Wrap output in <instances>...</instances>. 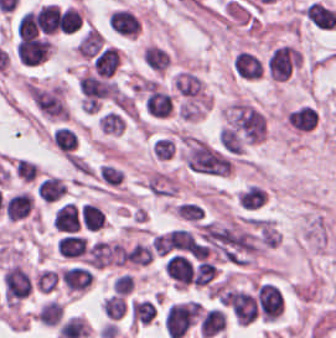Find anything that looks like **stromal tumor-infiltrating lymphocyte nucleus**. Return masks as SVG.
Wrapping results in <instances>:
<instances>
[{"instance_id":"4","label":"stromal tumor-infiltrating lymphocyte nucleus","mask_w":336,"mask_h":338,"mask_svg":"<svg viewBox=\"0 0 336 338\" xmlns=\"http://www.w3.org/2000/svg\"><path fill=\"white\" fill-rule=\"evenodd\" d=\"M106 26L115 35L132 37L138 29V19L125 7H118L106 16Z\"/></svg>"},{"instance_id":"9","label":"stromal tumor-infiltrating lymphocyte nucleus","mask_w":336,"mask_h":338,"mask_svg":"<svg viewBox=\"0 0 336 338\" xmlns=\"http://www.w3.org/2000/svg\"><path fill=\"white\" fill-rule=\"evenodd\" d=\"M306 17L315 27L322 29H332L336 21L332 9L313 0L306 9Z\"/></svg>"},{"instance_id":"12","label":"stromal tumor-infiltrating lymphocyte nucleus","mask_w":336,"mask_h":338,"mask_svg":"<svg viewBox=\"0 0 336 338\" xmlns=\"http://www.w3.org/2000/svg\"><path fill=\"white\" fill-rule=\"evenodd\" d=\"M145 105L152 114L167 115L172 107L171 95L151 87Z\"/></svg>"},{"instance_id":"3","label":"stromal tumor-infiltrating lymphocyte nucleus","mask_w":336,"mask_h":338,"mask_svg":"<svg viewBox=\"0 0 336 338\" xmlns=\"http://www.w3.org/2000/svg\"><path fill=\"white\" fill-rule=\"evenodd\" d=\"M84 261L89 269H99L114 264L112 243L98 238L90 240L86 245Z\"/></svg>"},{"instance_id":"14","label":"stromal tumor-infiltrating lymphocyte nucleus","mask_w":336,"mask_h":338,"mask_svg":"<svg viewBox=\"0 0 336 338\" xmlns=\"http://www.w3.org/2000/svg\"><path fill=\"white\" fill-rule=\"evenodd\" d=\"M124 122L119 109H105L98 117V125L104 133H121Z\"/></svg>"},{"instance_id":"1","label":"stromal tumor-infiltrating lymphocyte nucleus","mask_w":336,"mask_h":338,"mask_svg":"<svg viewBox=\"0 0 336 338\" xmlns=\"http://www.w3.org/2000/svg\"><path fill=\"white\" fill-rule=\"evenodd\" d=\"M162 323L167 337L180 338L191 324L188 302L168 305Z\"/></svg>"},{"instance_id":"8","label":"stromal tumor-infiltrating lymphocyte nucleus","mask_w":336,"mask_h":338,"mask_svg":"<svg viewBox=\"0 0 336 338\" xmlns=\"http://www.w3.org/2000/svg\"><path fill=\"white\" fill-rule=\"evenodd\" d=\"M32 208L29 194L19 192L7 198L4 213L7 220H18L26 217Z\"/></svg>"},{"instance_id":"17","label":"stromal tumor-infiltrating lymphocyte nucleus","mask_w":336,"mask_h":338,"mask_svg":"<svg viewBox=\"0 0 336 338\" xmlns=\"http://www.w3.org/2000/svg\"><path fill=\"white\" fill-rule=\"evenodd\" d=\"M95 176L105 185L117 186L121 182L122 171L109 163H101L97 166Z\"/></svg>"},{"instance_id":"16","label":"stromal tumor-infiltrating lymphocyte nucleus","mask_w":336,"mask_h":338,"mask_svg":"<svg viewBox=\"0 0 336 338\" xmlns=\"http://www.w3.org/2000/svg\"><path fill=\"white\" fill-rule=\"evenodd\" d=\"M104 314L108 319H117L125 311V301L121 295H108L100 304Z\"/></svg>"},{"instance_id":"13","label":"stromal tumor-infiltrating lymphocyte nucleus","mask_w":336,"mask_h":338,"mask_svg":"<svg viewBox=\"0 0 336 338\" xmlns=\"http://www.w3.org/2000/svg\"><path fill=\"white\" fill-rule=\"evenodd\" d=\"M224 313L218 308H211L204 313L201 322V336L212 337L222 331Z\"/></svg>"},{"instance_id":"2","label":"stromal tumor-infiltrating lymphocyte nucleus","mask_w":336,"mask_h":338,"mask_svg":"<svg viewBox=\"0 0 336 338\" xmlns=\"http://www.w3.org/2000/svg\"><path fill=\"white\" fill-rule=\"evenodd\" d=\"M92 278L90 269L84 263H70L58 274V282L74 294L88 289Z\"/></svg>"},{"instance_id":"10","label":"stromal tumor-infiltrating lymphocyte nucleus","mask_w":336,"mask_h":338,"mask_svg":"<svg viewBox=\"0 0 336 338\" xmlns=\"http://www.w3.org/2000/svg\"><path fill=\"white\" fill-rule=\"evenodd\" d=\"M141 57L148 69L154 71H163L169 62L168 51L156 44L145 46Z\"/></svg>"},{"instance_id":"6","label":"stromal tumor-infiltrating lymphocyte nucleus","mask_w":336,"mask_h":338,"mask_svg":"<svg viewBox=\"0 0 336 338\" xmlns=\"http://www.w3.org/2000/svg\"><path fill=\"white\" fill-rule=\"evenodd\" d=\"M66 189L65 183L52 175L41 176L35 184L36 198L44 203H58Z\"/></svg>"},{"instance_id":"15","label":"stromal tumor-infiltrating lymphocyte nucleus","mask_w":336,"mask_h":338,"mask_svg":"<svg viewBox=\"0 0 336 338\" xmlns=\"http://www.w3.org/2000/svg\"><path fill=\"white\" fill-rule=\"evenodd\" d=\"M264 191L256 185L245 186L236 198L242 208H257L263 201Z\"/></svg>"},{"instance_id":"19","label":"stromal tumor-infiltrating lymphocyte nucleus","mask_w":336,"mask_h":338,"mask_svg":"<svg viewBox=\"0 0 336 338\" xmlns=\"http://www.w3.org/2000/svg\"><path fill=\"white\" fill-rule=\"evenodd\" d=\"M152 254L147 246L141 243H134L125 253L123 260L136 264H147L150 262Z\"/></svg>"},{"instance_id":"20","label":"stromal tumor-infiltrating lymphocyte nucleus","mask_w":336,"mask_h":338,"mask_svg":"<svg viewBox=\"0 0 336 338\" xmlns=\"http://www.w3.org/2000/svg\"><path fill=\"white\" fill-rule=\"evenodd\" d=\"M152 151L156 158L169 159L173 154V146L168 138L157 137L151 142Z\"/></svg>"},{"instance_id":"5","label":"stromal tumor-infiltrating lymphocyte nucleus","mask_w":336,"mask_h":338,"mask_svg":"<svg viewBox=\"0 0 336 338\" xmlns=\"http://www.w3.org/2000/svg\"><path fill=\"white\" fill-rule=\"evenodd\" d=\"M88 236L85 233H76L62 236L56 240L59 256L83 262L87 249Z\"/></svg>"},{"instance_id":"18","label":"stromal tumor-infiltrating lymphocyte nucleus","mask_w":336,"mask_h":338,"mask_svg":"<svg viewBox=\"0 0 336 338\" xmlns=\"http://www.w3.org/2000/svg\"><path fill=\"white\" fill-rule=\"evenodd\" d=\"M62 309L58 302L55 300H48L41 305L37 318L41 324L44 325H53L60 318Z\"/></svg>"},{"instance_id":"7","label":"stromal tumor-infiltrating lymphocyte nucleus","mask_w":336,"mask_h":338,"mask_svg":"<svg viewBox=\"0 0 336 338\" xmlns=\"http://www.w3.org/2000/svg\"><path fill=\"white\" fill-rule=\"evenodd\" d=\"M201 86L198 76L188 70H181L172 80L173 92L181 98L197 96Z\"/></svg>"},{"instance_id":"11","label":"stromal tumor-infiltrating lymphocyte nucleus","mask_w":336,"mask_h":338,"mask_svg":"<svg viewBox=\"0 0 336 338\" xmlns=\"http://www.w3.org/2000/svg\"><path fill=\"white\" fill-rule=\"evenodd\" d=\"M78 137L73 128L57 126L51 142L55 149L61 153L73 154L75 152Z\"/></svg>"}]
</instances>
